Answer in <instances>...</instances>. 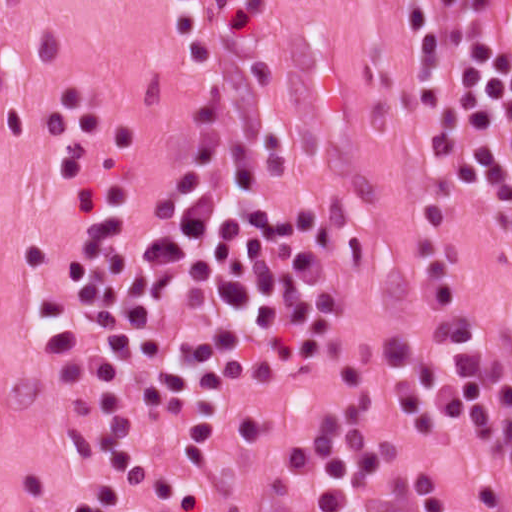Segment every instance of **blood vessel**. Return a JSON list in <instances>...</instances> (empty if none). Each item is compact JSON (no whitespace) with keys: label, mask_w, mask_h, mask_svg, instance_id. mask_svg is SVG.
Masks as SVG:
<instances>
[{"label":"blood vessel","mask_w":512,"mask_h":512,"mask_svg":"<svg viewBox=\"0 0 512 512\" xmlns=\"http://www.w3.org/2000/svg\"><path fill=\"white\" fill-rule=\"evenodd\" d=\"M487 64L493 77L512 79V0H487Z\"/></svg>","instance_id":"obj_1"}]
</instances>
